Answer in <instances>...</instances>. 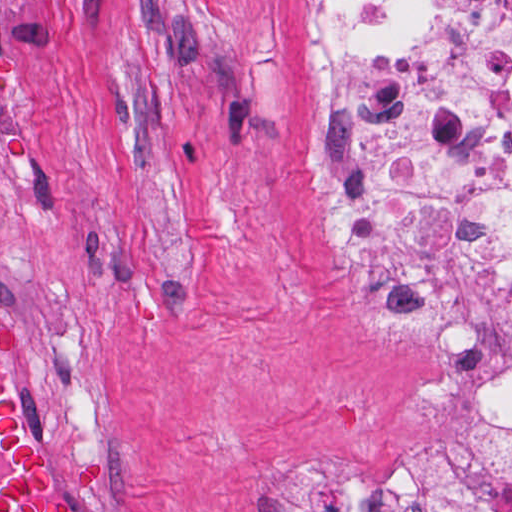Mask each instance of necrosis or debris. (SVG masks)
Here are the masks:
<instances>
[{
	"instance_id": "1",
	"label": "necrosis or debris",
	"mask_w": 512,
	"mask_h": 512,
	"mask_svg": "<svg viewBox=\"0 0 512 512\" xmlns=\"http://www.w3.org/2000/svg\"><path fill=\"white\" fill-rule=\"evenodd\" d=\"M297 117L354 309L431 342L463 409L395 489L282 456L247 512H512V0H312Z\"/></svg>"
}]
</instances>
